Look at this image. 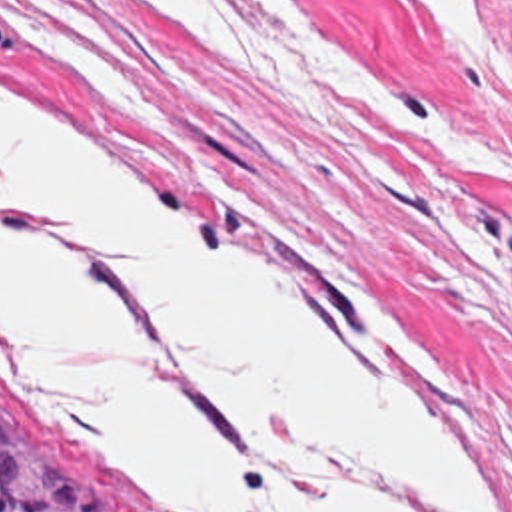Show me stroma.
<instances>
[{
    "mask_svg": "<svg viewBox=\"0 0 512 512\" xmlns=\"http://www.w3.org/2000/svg\"><path fill=\"white\" fill-rule=\"evenodd\" d=\"M304 1L512 163V0H474L496 79L412 0L400 21L380 0ZM0 85L296 267L498 512H512L510 189L428 145L354 133L418 199L388 209L304 131L166 61L122 0H0ZM0 394L75 452L116 512H178L1 343Z\"/></svg>",
    "mask_w": 512,
    "mask_h": 512,
    "instance_id": "stroma-1",
    "label": "stroma"
}]
</instances>
